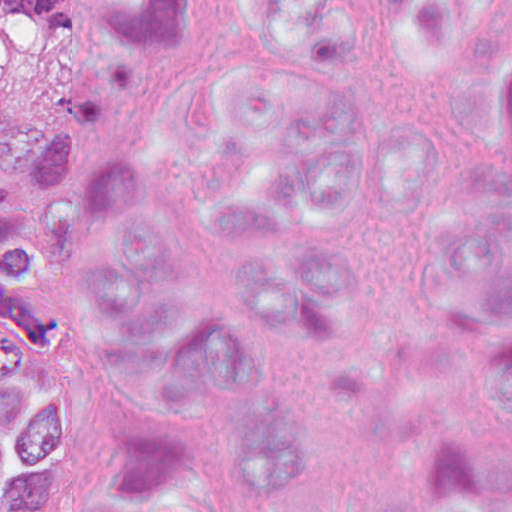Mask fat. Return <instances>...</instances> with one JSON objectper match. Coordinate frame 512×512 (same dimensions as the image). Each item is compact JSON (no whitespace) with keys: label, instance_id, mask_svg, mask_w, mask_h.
<instances>
[{"label":"fat","instance_id":"1","mask_svg":"<svg viewBox=\"0 0 512 512\" xmlns=\"http://www.w3.org/2000/svg\"><path fill=\"white\" fill-rule=\"evenodd\" d=\"M34 36L33 19H0V69L21 60Z\"/></svg>","mask_w":512,"mask_h":512}]
</instances>
